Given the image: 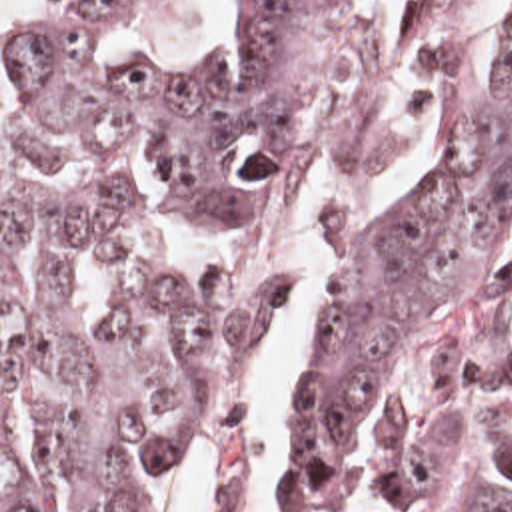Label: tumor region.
Wrapping results in <instances>:
<instances>
[{
  "label": "tumor region",
  "instance_id": "obj_1",
  "mask_svg": "<svg viewBox=\"0 0 512 512\" xmlns=\"http://www.w3.org/2000/svg\"><path fill=\"white\" fill-rule=\"evenodd\" d=\"M132 0L0 37V512H154L188 416L280 321L296 277L168 279L112 325L74 307L140 237L156 161L186 217L338 169L318 105L348 0H238L242 43L110 63ZM469 0H420L428 181L344 241L304 352L300 512H512V9L467 65ZM228 456L216 512H238Z\"/></svg>",
  "mask_w": 512,
  "mask_h": 512
}]
</instances>
